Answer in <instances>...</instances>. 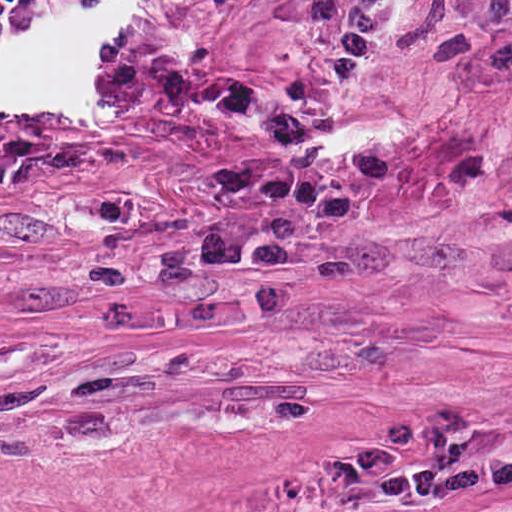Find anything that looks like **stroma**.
<instances>
[{
	"label": "stroma",
	"instance_id": "35a3bbf8",
	"mask_svg": "<svg viewBox=\"0 0 512 512\" xmlns=\"http://www.w3.org/2000/svg\"><path fill=\"white\" fill-rule=\"evenodd\" d=\"M512 0H0V512H512Z\"/></svg>",
	"mask_w": 512,
	"mask_h": 512
}]
</instances>
